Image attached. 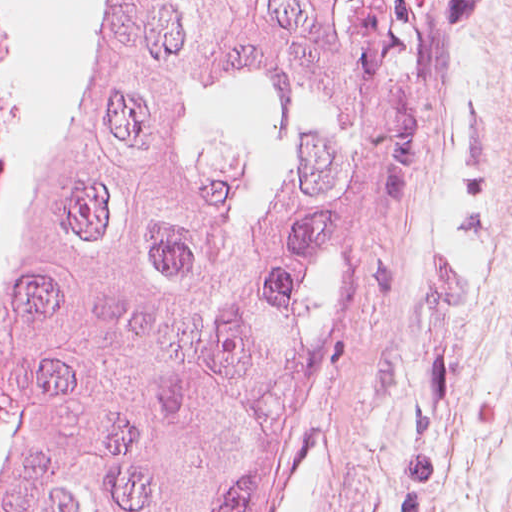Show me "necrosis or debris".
Segmentation results:
<instances>
[{
	"mask_svg": "<svg viewBox=\"0 0 512 512\" xmlns=\"http://www.w3.org/2000/svg\"><path fill=\"white\" fill-rule=\"evenodd\" d=\"M24 71L23 45L14 34L12 15L0 0V154ZM0 156V205L8 177Z\"/></svg>",
	"mask_w": 512,
	"mask_h": 512,
	"instance_id": "1",
	"label": "necrosis or debris"
}]
</instances>
